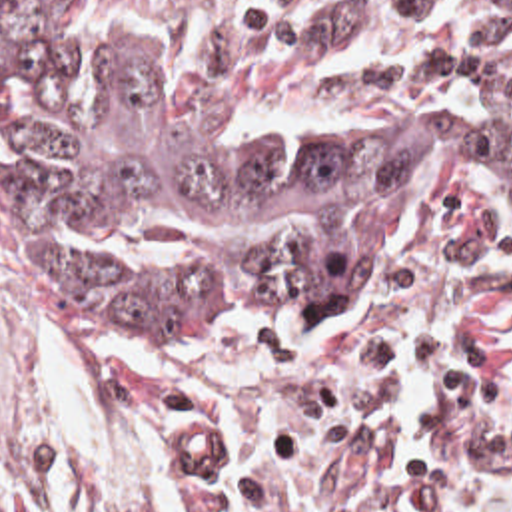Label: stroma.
Here are the masks:
<instances>
[{"label":"stroma","mask_w":512,"mask_h":512,"mask_svg":"<svg viewBox=\"0 0 512 512\" xmlns=\"http://www.w3.org/2000/svg\"><path fill=\"white\" fill-rule=\"evenodd\" d=\"M230 119L385 111L512 135V115L339 89L321 55L469 0H108ZM0 451L38 512H512V229L429 189L335 325L112 335L0 269Z\"/></svg>","instance_id":"1"}]
</instances>
